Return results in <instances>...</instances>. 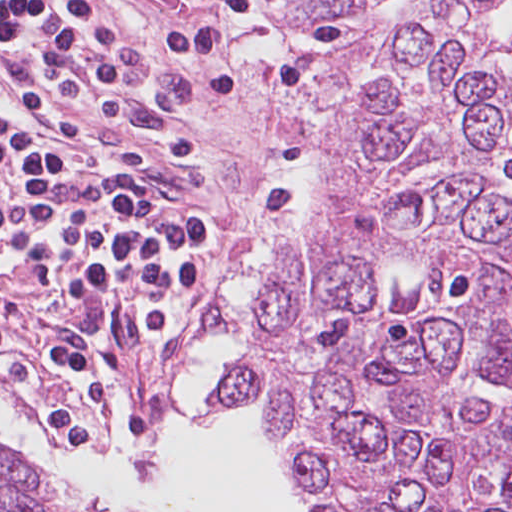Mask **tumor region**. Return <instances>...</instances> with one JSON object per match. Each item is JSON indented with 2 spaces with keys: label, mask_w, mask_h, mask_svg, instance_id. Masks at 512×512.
<instances>
[{
  "label": "tumor region",
  "mask_w": 512,
  "mask_h": 512,
  "mask_svg": "<svg viewBox=\"0 0 512 512\" xmlns=\"http://www.w3.org/2000/svg\"><path fill=\"white\" fill-rule=\"evenodd\" d=\"M259 403L317 512H512V0L424 7L348 72L208 406ZM0 512L66 511L0 447Z\"/></svg>",
  "instance_id": "e687c5a6"
}]
</instances>
